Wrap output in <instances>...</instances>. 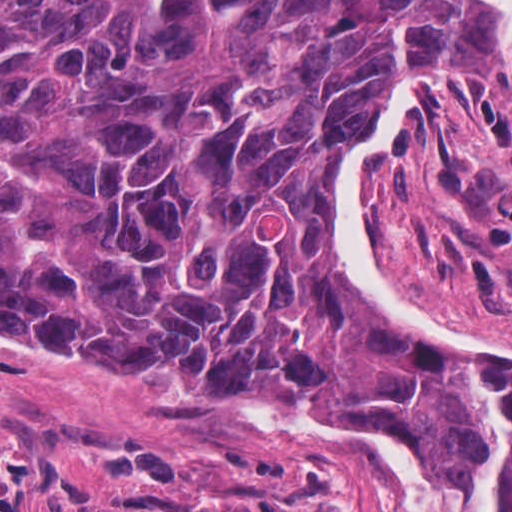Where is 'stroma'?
<instances>
[{
	"label": "stroma",
	"instance_id": "stroma-1",
	"mask_svg": "<svg viewBox=\"0 0 512 512\" xmlns=\"http://www.w3.org/2000/svg\"><path fill=\"white\" fill-rule=\"evenodd\" d=\"M488 15L500 76L396 132L376 179L371 252L401 312L512 351V67ZM362 141L340 151L322 178L340 276L359 310L414 357L451 351L512 368L505 352L437 344L372 294L369 305L360 296L340 254L331 193ZM29 344L62 359L0 352V512H123L118 494L130 483L197 496L242 485L284 498L302 470L319 464L335 512H402L379 459L312 447L248 417L264 400L294 399L407 446L384 406L318 388L176 392L150 373L82 365Z\"/></svg>",
	"mask_w": 512,
	"mask_h": 512
}]
</instances>
